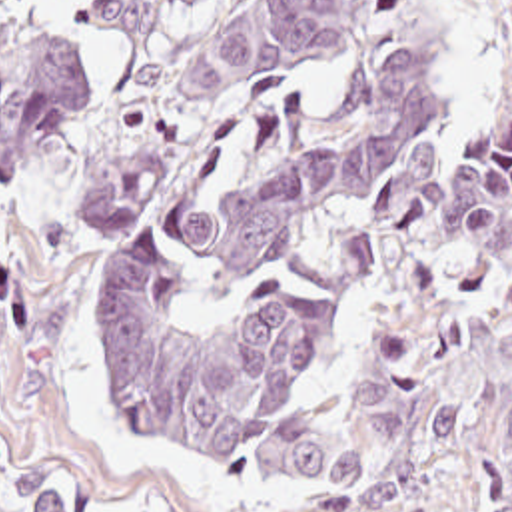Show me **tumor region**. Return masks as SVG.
Returning <instances> with one entry per match:
<instances>
[{
	"label": "tumor region",
	"mask_w": 512,
	"mask_h": 512,
	"mask_svg": "<svg viewBox=\"0 0 512 512\" xmlns=\"http://www.w3.org/2000/svg\"><path fill=\"white\" fill-rule=\"evenodd\" d=\"M11 0H0L5 8ZM205 0H93L87 24L157 36ZM340 70L344 112L303 158L191 230L143 246L105 278L95 344L125 414L173 454L231 460L245 448L275 507H346L388 495L438 458L464 386L392 332L336 414L289 406L322 358L334 302L269 284L203 334L173 322L185 290L239 272L320 210L494 328L508 390L482 408L486 512H512V112L450 156L432 126L440 62L428 0H235L163 62L97 140L79 182L75 242L143 212L231 114L269 84ZM95 88L61 34L0 32V180L39 166ZM29 512H123L21 456Z\"/></svg>",
	"instance_id": "e687c5a6"
}]
</instances>
